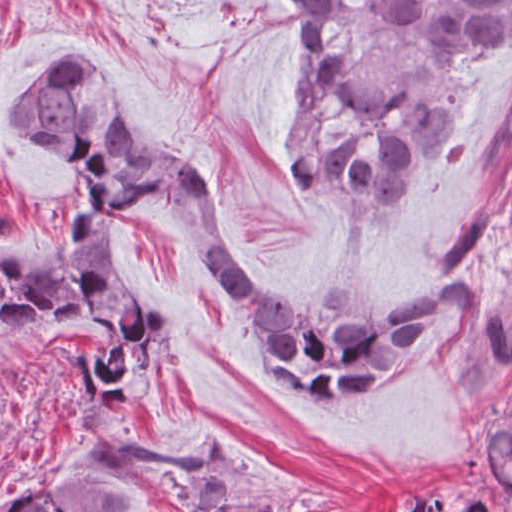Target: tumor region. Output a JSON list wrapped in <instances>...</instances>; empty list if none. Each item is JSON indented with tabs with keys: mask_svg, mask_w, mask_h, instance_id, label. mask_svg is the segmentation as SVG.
Instances as JSON below:
<instances>
[{
	"mask_svg": "<svg viewBox=\"0 0 512 512\" xmlns=\"http://www.w3.org/2000/svg\"><path fill=\"white\" fill-rule=\"evenodd\" d=\"M103 2L111 0H101ZM291 51L283 102L287 185L295 200L382 222L453 173L469 108L366 92L332 12V0H265ZM399 47L457 65L512 37V0H380ZM49 148L76 193L30 257L0 248V311L20 320L85 316L114 333L117 351H78L87 387L65 423L76 446L3 512H290L286 489L224 429L199 427L183 446L138 440L132 389L143 376L162 314L134 304L117 253V214L133 197L158 199L212 275L239 305L280 382L345 400L403 376L481 311L472 279L431 299L391 302L337 272L312 304L264 290L219 221L205 171L159 153L132 132L102 68L86 53L57 61L5 118ZM486 376H512V304L482 311ZM512 494V394L479 462ZM391 512H504L469 498L445 505L427 494Z\"/></svg>",
	"mask_w": 512,
	"mask_h": 512,
	"instance_id": "tumor-region-1",
	"label": "tumor region"
}]
</instances>
